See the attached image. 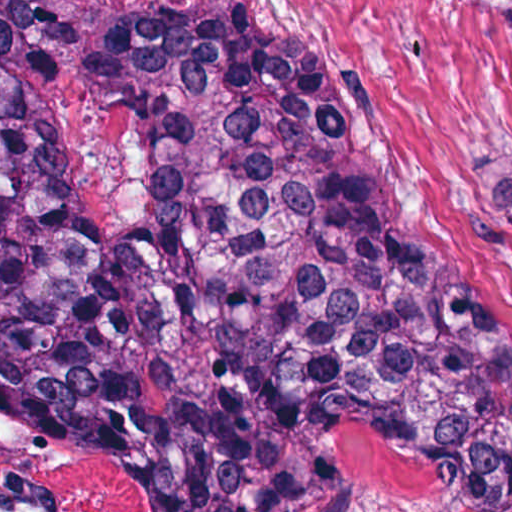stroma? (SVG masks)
Listing matches in <instances>:
<instances>
[{"label": "stroma", "instance_id": "obj_1", "mask_svg": "<svg viewBox=\"0 0 512 512\" xmlns=\"http://www.w3.org/2000/svg\"><path fill=\"white\" fill-rule=\"evenodd\" d=\"M67 1L244 52L329 67L355 109L367 172L394 218L467 281L512 352V0ZM326 422L356 512H442L443 479L372 436ZM0 512H153L113 447L21 386H0Z\"/></svg>", "mask_w": 512, "mask_h": 512}]
</instances>
